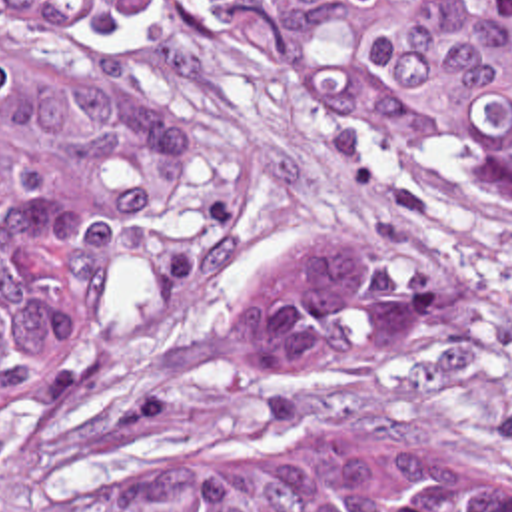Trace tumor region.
I'll return each instance as SVG.
<instances>
[{
    "mask_svg": "<svg viewBox=\"0 0 512 512\" xmlns=\"http://www.w3.org/2000/svg\"><path fill=\"white\" fill-rule=\"evenodd\" d=\"M133 1L0 0L65 31L49 59L0 63V440L45 424L63 384L97 424L149 438L137 478L37 512H512V450L263 436L203 398H287L436 335L448 279L426 251L299 259L239 283L145 378L81 370L163 177L161 109L117 37ZM165 1L512 217V0Z\"/></svg>",
    "mask_w": 512,
    "mask_h": 512,
    "instance_id": "e687c5a6",
    "label": "tumor region"
}]
</instances>
